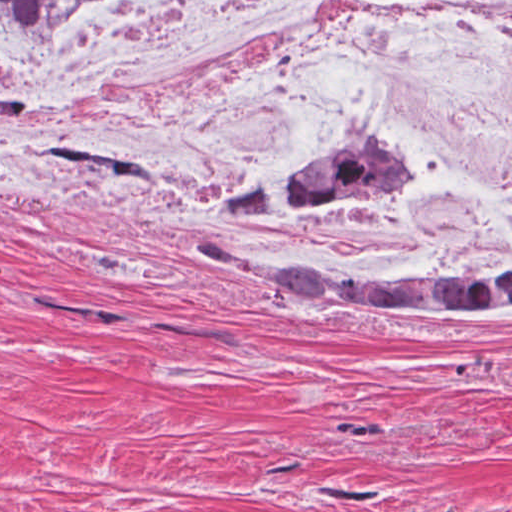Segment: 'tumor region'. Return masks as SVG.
<instances>
[{"label": "tumor region", "instance_id": "e687c5a6", "mask_svg": "<svg viewBox=\"0 0 512 512\" xmlns=\"http://www.w3.org/2000/svg\"><path fill=\"white\" fill-rule=\"evenodd\" d=\"M72 0H1V29L46 15ZM414 156L380 154L316 169L293 193L289 207L307 219H323L335 210L382 198L416 185ZM205 260L254 276L266 283L298 289L343 308H446L503 306L512 303V257L491 277L460 283L400 281L348 282L311 265L288 270L251 263L206 235L192 240ZM1 512H4L1 509Z\"/></svg>", "mask_w": 512, "mask_h": 512}]
</instances>
